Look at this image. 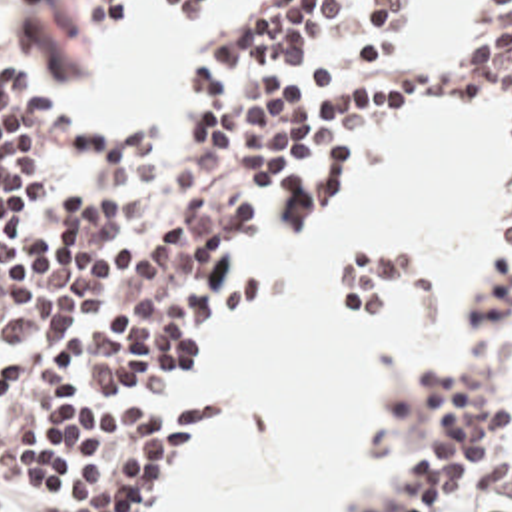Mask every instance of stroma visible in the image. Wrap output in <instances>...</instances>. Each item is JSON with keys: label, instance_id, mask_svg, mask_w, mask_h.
Masks as SVG:
<instances>
[{"label": "stroma", "instance_id": "35a3bbf8", "mask_svg": "<svg viewBox=\"0 0 512 512\" xmlns=\"http://www.w3.org/2000/svg\"><path fill=\"white\" fill-rule=\"evenodd\" d=\"M482 1L484 0L460 1L454 29H412L418 0H406L402 9V19L388 45L386 61L404 63L410 59H432L454 47L476 43L500 23V19L492 17H484L472 23L474 11L480 7ZM270 3L272 0H238L234 9L224 19V23L176 63L170 87L162 95L150 99L144 105L154 111L164 129V153L160 161L148 165L134 179L98 183L92 181L80 169L78 155L70 151L58 157V183L54 191L114 193L118 211L128 217L154 205L166 191L172 189L180 149L186 137L190 135L192 127L202 119L198 95L194 89L188 87L184 79L190 63L212 49L242 41L248 35H252L256 27L262 23ZM128 5L130 0H124V13L120 21L102 33L90 27L84 21L82 13L72 5L9 7L0 13V61L11 65L30 91L46 99L52 111L68 115L80 123H98L110 117L138 111L74 109L60 99L62 85L80 79L94 67H98L102 59L104 35L122 27L128 13ZM158 19L162 25L170 27L164 15V0H160ZM202 19L172 29L190 35ZM404 115H416L426 119L438 135H470L498 149L508 161V201L504 205L494 235V253L486 265L484 277L462 321V341L458 355L446 365L440 345L424 371L418 367L412 355L406 353L390 355L386 363L378 369L374 377V421L368 440L364 470L372 468L380 458L382 462L372 484L354 498L352 512H388V494L400 476L402 452L416 450L428 454L438 444L434 436L416 432L414 409L426 395L450 385H470L480 391L482 399L502 405V448L486 466L478 470V474L470 480L460 498L448 502V506L438 508L434 512H512V125L504 119L500 109H454L450 113ZM396 117L366 127L350 139L346 149L356 153L360 171L354 183L348 187L344 199L326 217L334 215L346 203L352 191L360 185L362 153L366 143ZM286 233L296 231L284 227L270 209L266 221L260 225L244 257L242 269L280 267L292 273ZM294 303L296 295L292 289L290 297L280 305L244 315L224 325L204 347L196 367L178 385L166 391L160 397V401H188L212 393H222L232 399L222 363L224 343L246 337L256 327L266 323L274 313L284 311ZM234 413L236 407L232 401L216 434L228 421H232ZM212 450L214 440L198 458L192 472H196L202 464L208 462ZM186 478L178 482L176 490L186 482ZM172 494L164 496L148 512H156V508L162 502H166Z\"/></svg>", "mask_w": 512, "mask_h": 512}]
</instances>
